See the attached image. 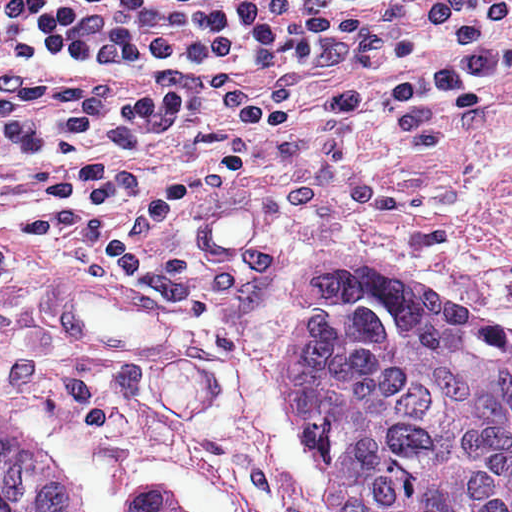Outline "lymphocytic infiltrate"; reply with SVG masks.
Wrapping results in <instances>:
<instances>
[{
    "instance_id": "1",
    "label": "lymphocytic infiltrate",
    "mask_w": 512,
    "mask_h": 512,
    "mask_svg": "<svg viewBox=\"0 0 512 512\" xmlns=\"http://www.w3.org/2000/svg\"><path fill=\"white\" fill-rule=\"evenodd\" d=\"M511 65L512 0H0V79L255 66L350 108L349 128L450 99ZM253 95L202 85L106 99L38 89L0 102V264L24 247L90 239L115 284L197 301L154 271L152 233L174 202L255 180L279 153L228 136L200 169L167 181L139 142Z\"/></svg>"
}]
</instances>
